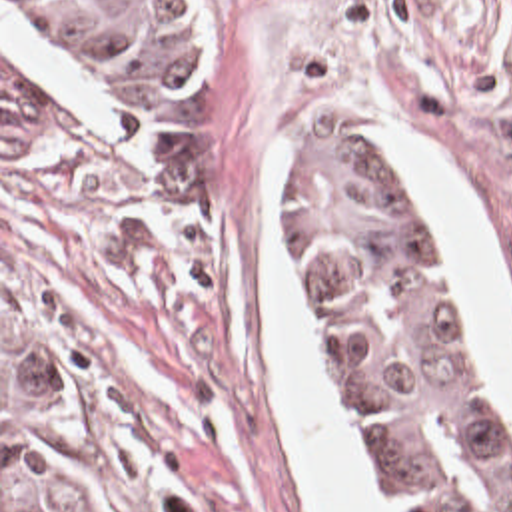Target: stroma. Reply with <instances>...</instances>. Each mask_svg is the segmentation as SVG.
<instances>
[{"label": "stroma", "mask_w": 512, "mask_h": 512, "mask_svg": "<svg viewBox=\"0 0 512 512\" xmlns=\"http://www.w3.org/2000/svg\"><path fill=\"white\" fill-rule=\"evenodd\" d=\"M214 72L180 110H98L0 0L2 290L62 372L116 512H313L268 358L258 250L272 234L313 389L391 497L300 298L280 190L300 144L351 142L403 174L419 244L453 284L512 477V407L389 128L423 132L481 210L512 312V0H208ZM2 62L46 98V138L2 154Z\"/></svg>", "instance_id": "35a3bbf8"}]
</instances>
